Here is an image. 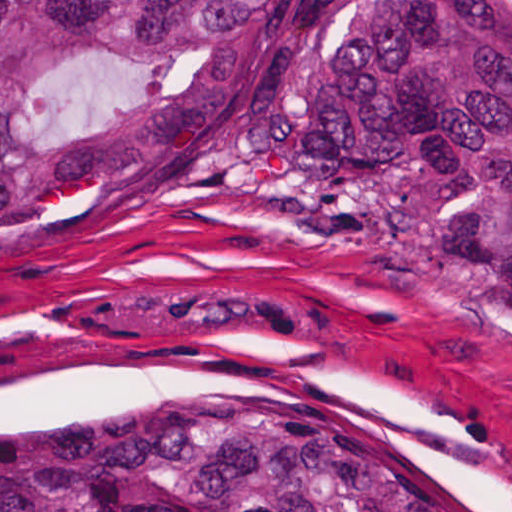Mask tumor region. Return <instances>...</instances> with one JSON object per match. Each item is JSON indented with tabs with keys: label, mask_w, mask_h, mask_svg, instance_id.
<instances>
[{
	"label": "tumor region",
	"mask_w": 512,
	"mask_h": 512,
	"mask_svg": "<svg viewBox=\"0 0 512 512\" xmlns=\"http://www.w3.org/2000/svg\"><path fill=\"white\" fill-rule=\"evenodd\" d=\"M124 164L512 322V0H0V192ZM0 512L489 511L261 391L2 418Z\"/></svg>",
	"instance_id": "obj_1"
}]
</instances>
